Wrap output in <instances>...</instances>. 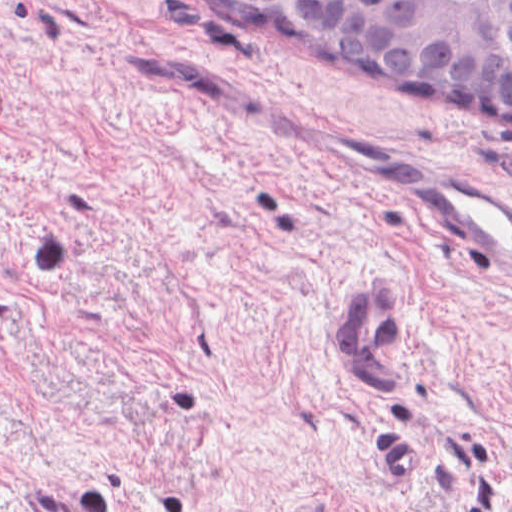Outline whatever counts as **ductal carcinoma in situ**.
Returning <instances> with one entry per match:
<instances>
[{"mask_svg":"<svg viewBox=\"0 0 512 512\" xmlns=\"http://www.w3.org/2000/svg\"><path fill=\"white\" fill-rule=\"evenodd\" d=\"M329 72L512 132V0H173Z\"/></svg>","mask_w":512,"mask_h":512,"instance_id":"obj_1","label":"ductal carcinoma in situ"}]
</instances>
